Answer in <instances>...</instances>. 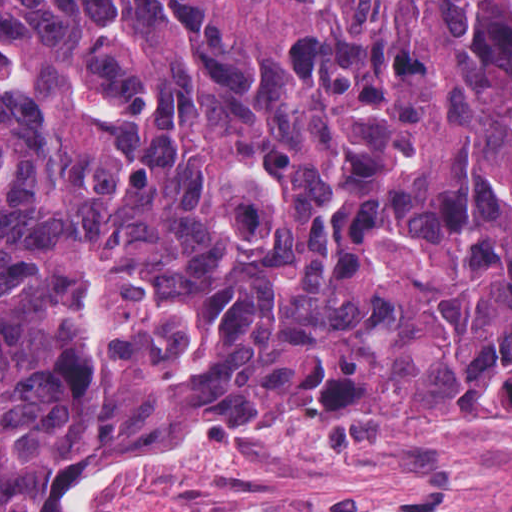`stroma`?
<instances>
[{
	"mask_svg": "<svg viewBox=\"0 0 512 512\" xmlns=\"http://www.w3.org/2000/svg\"><path fill=\"white\" fill-rule=\"evenodd\" d=\"M512 32V5L493 0ZM66 512H512V444L312 419L218 421L150 463L76 477Z\"/></svg>",
	"mask_w": 512,
	"mask_h": 512,
	"instance_id": "stroma-1",
	"label": "stroma"
}]
</instances>
